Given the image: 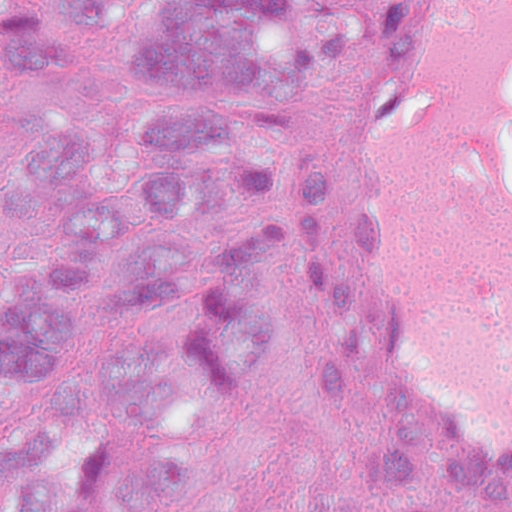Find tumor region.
<instances>
[{
    "instance_id": "obj_1",
    "label": "tumor region",
    "mask_w": 512,
    "mask_h": 512,
    "mask_svg": "<svg viewBox=\"0 0 512 512\" xmlns=\"http://www.w3.org/2000/svg\"><path fill=\"white\" fill-rule=\"evenodd\" d=\"M135 7L0 0V512H239L187 431L270 332L272 160L371 27L361 0ZM126 18L102 82L89 30ZM269 512L497 511L409 445H331Z\"/></svg>"
}]
</instances>
